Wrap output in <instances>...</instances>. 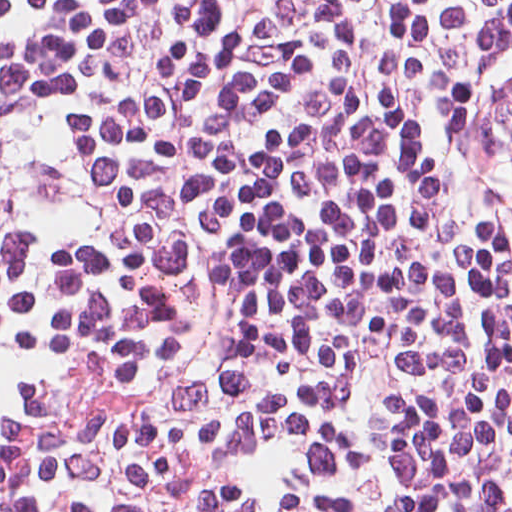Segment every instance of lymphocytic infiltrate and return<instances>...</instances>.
<instances>
[{
	"mask_svg": "<svg viewBox=\"0 0 512 512\" xmlns=\"http://www.w3.org/2000/svg\"><path fill=\"white\" fill-rule=\"evenodd\" d=\"M0 512H512V256L229 0H0Z\"/></svg>",
	"mask_w": 512,
	"mask_h": 512,
	"instance_id": "lymphocytic-infiltrate-1",
	"label": "lymphocytic infiltrate"
}]
</instances>
